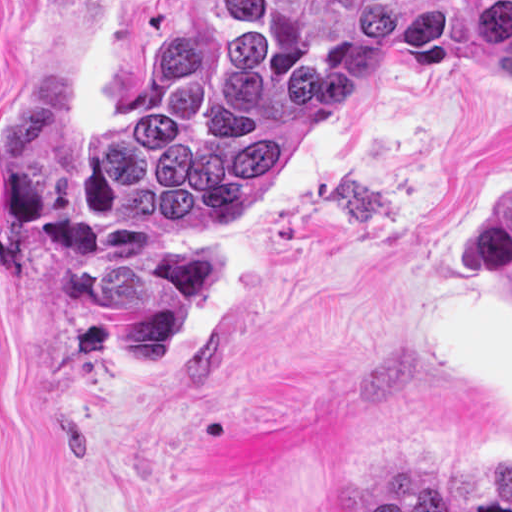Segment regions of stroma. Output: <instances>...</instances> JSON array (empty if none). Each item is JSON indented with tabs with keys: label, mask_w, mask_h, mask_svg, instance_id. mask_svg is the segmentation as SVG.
<instances>
[{
	"label": "stroma",
	"mask_w": 512,
	"mask_h": 512,
	"mask_svg": "<svg viewBox=\"0 0 512 512\" xmlns=\"http://www.w3.org/2000/svg\"><path fill=\"white\" fill-rule=\"evenodd\" d=\"M177 0H0V96L65 32L77 108L122 118ZM512 187V76L346 68L320 122L205 235L230 279L167 372L67 367L48 264L0 241V512H512V404L428 347L484 279L475 217Z\"/></svg>",
	"instance_id": "35a3bbf8"
}]
</instances>
